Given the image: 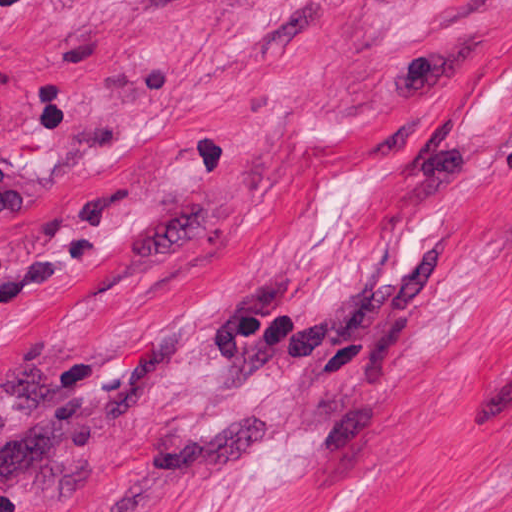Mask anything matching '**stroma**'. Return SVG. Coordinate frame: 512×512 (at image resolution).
<instances>
[{
	"label": "stroma",
	"mask_w": 512,
	"mask_h": 512,
	"mask_svg": "<svg viewBox=\"0 0 512 512\" xmlns=\"http://www.w3.org/2000/svg\"><path fill=\"white\" fill-rule=\"evenodd\" d=\"M0 512H512V0H0Z\"/></svg>",
	"instance_id": "1"
}]
</instances>
